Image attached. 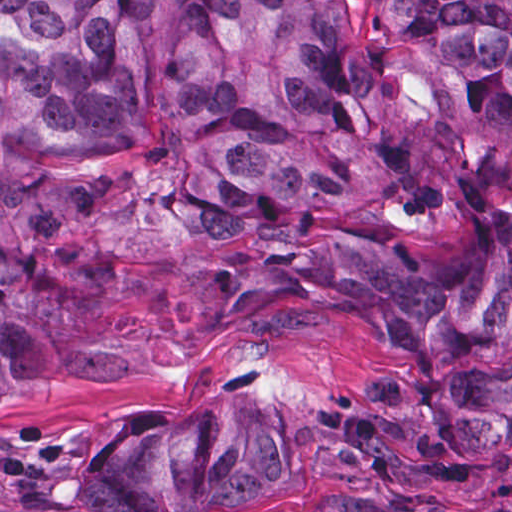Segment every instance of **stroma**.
Wrapping results in <instances>:
<instances>
[{"instance_id":"1","label":"stroma","mask_w":512,"mask_h":512,"mask_svg":"<svg viewBox=\"0 0 512 512\" xmlns=\"http://www.w3.org/2000/svg\"><path fill=\"white\" fill-rule=\"evenodd\" d=\"M380 364L368 317L298 306L158 349L104 385L18 387L0 398V512H90L87 477L123 425L204 405L261 419L292 450V475L238 506L198 512H276L322 493L512 512V456L467 469H352L324 456L320 421Z\"/></svg>"}]
</instances>
